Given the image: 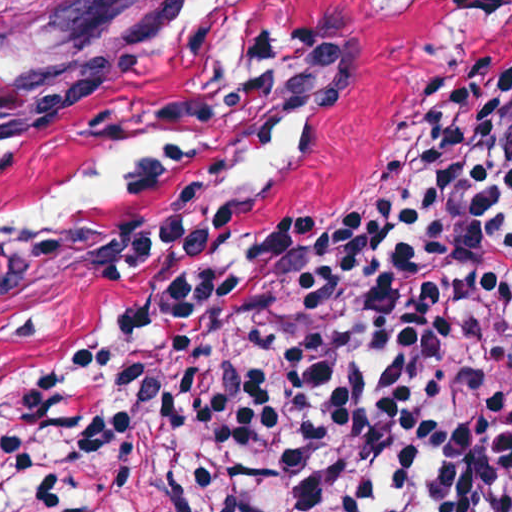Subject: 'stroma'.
I'll return each mask as SVG.
<instances>
[{"label":"stroma","instance_id":"obj_1","mask_svg":"<svg viewBox=\"0 0 512 512\" xmlns=\"http://www.w3.org/2000/svg\"><path fill=\"white\" fill-rule=\"evenodd\" d=\"M181 1L24 0L0 21V427L102 300L124 203L307 216L383 167L456 52L431 0H275L205 50L175 44Z\"/></svg>","mask_w":512,"mask_h":512}]
</instances>
